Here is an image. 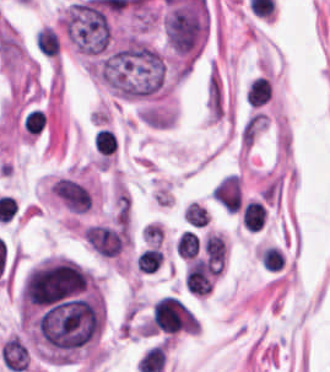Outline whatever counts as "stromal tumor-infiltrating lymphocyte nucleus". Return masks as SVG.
<instances>
[{
  "label": "stromal tumor-infiltrating lymphocyte nucleus",
  "mask_w": 330,
  "mask_h": 372,
  "mask_svg": "<svg viewBox=\"0 0 330 372\" xmlns=\"http://www.w3.org/2000/svg\"><path fill=\"white\" fill-rule=\"evenodd\" d=\"M271 91V85L269 79L262 76H254L248 83L245 99L255 106H261L264 104L269 93Z\"/></svg>",
  "instance_id": "1"
},
{
  "label": "stromal tumor-infiltrating lymphocyte nucleus",
  "mask_w": 330,
  "mask_h": 372,
  "mask_svg": "<svg viewBox=\"0 0 330 372\" xmlns=\"http://www.w3.org/2000/svg\"><path fill=\"white\" fill-rule=\"evenodd\" d=\"M242 222L245 227L257 230L264 223V206L260 200H247L242 205Z\"/></svg>",
  "instance_id": "2"
},
{
  "label": "stromal tumor-infiltrating lymphocyte nucleus",
  "mask_w": 330,
  "mask_h": 372,
  "mask_svg": "<svg viewBox=\"0 0 330 372\" xmlns=\"http://www.w3.org/2000/svg\"><path fill=\"white\" fill-rule=\"evenodd\" d=\"M199 249V237L194 231L184 230L175 243V250L185 258H192Z\"/></svg>",
  "instance_id": "3"
},
{
  "label": "stromal tumor-infiltrating lymphocyte nucleus",
  "mask_w": 330,
  "mask_h": 372,
  "mask_svg": "<svg viewBox=\"0 0 330 372\" xmlns=\"http://www.w3.org/2000/svg\"><path fill=\"white\" fill-rule=\"evenodd\" d=\"M163 259V253L159 248H146L136 259L140 271H153Z\"/></svg>",
  "instance_id": "4"
},
{
  "label": "stromal tumor-infiltrating lymphocyte nucleus",
  "mask_w": 330,
  "mask_h": 372,
  "mask_svg": "<svg viewBox=\"0 0 330 372\" xmlns=\"http://www.w3.org/2000/svg\"><path fill=\"white\" fill-rule=\"evenodd\" d=\"M115 135L110 128L99 127L93 136V148L97 152L109 153L115 146Z\"/></svg>",
  "instance_id": "5"
},
{
  "label": "stromal tumor-infiltrating lymphocyte nucleus",
  "mask_w": 330,
  "mask_h": 372,
  "mask_svg": "<svg viewBox=\"0 0 330 372\" xmlns=\"http://www.w3.org/2000/svg\"><path fill=\"white\" fill-rule=\"evenodd\" d=\"M185 220L193 226H204L207 223L205 206L191 200L185 205Z\"/></svg>",
  "instance_id": "6"
},
{
  "label": "stromal tumor-infiltrating lymphocyte nucleus",
  "mask_w": 330,
  "mask_h": 372,
  "mask_svg": "<svg viewBox=\"0 0 330 372\" xmlns=\"http://www.w3.org/2000/svg\"><path fill=\"white\" fill-rule=\"evenodd\" d=\"M283 261L281 252L275 246L260 250V263L265 270H278Z\"/></svg>",
  "instance_id": "7"
}]
</instances>
